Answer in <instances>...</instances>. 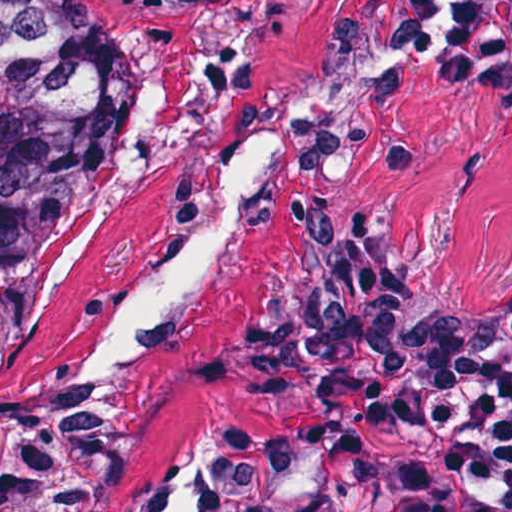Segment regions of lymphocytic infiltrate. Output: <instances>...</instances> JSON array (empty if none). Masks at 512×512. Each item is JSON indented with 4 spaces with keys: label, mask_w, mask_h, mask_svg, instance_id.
<instances>
[{
    "label": "lymphocytic infiltrate",
    "mask_w": 512,
    "mask_h": 512,
    "mask_svg": "<svg viewBox=\"0 0 512 512\" xmlns=\"http://www.w3.org/2000/svg\"><path fill=\"white\" fill-rule=\"evenodd\" d=\"M305 442L158 485L144 512H512V324L431 255L357 245L292 315Z\"/></svg>",
    "instance_id": "lymphocytic-infiltrate-1"
}]
</instances>
